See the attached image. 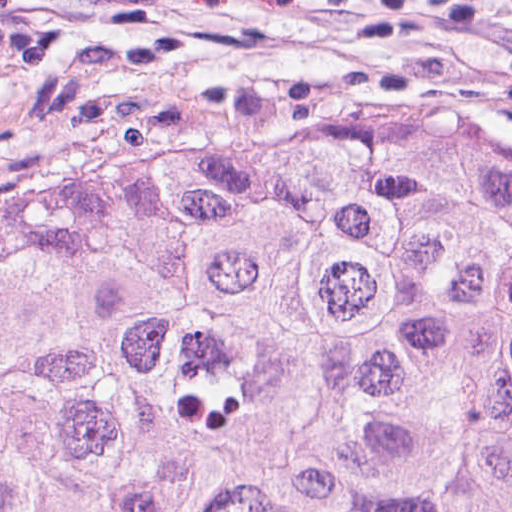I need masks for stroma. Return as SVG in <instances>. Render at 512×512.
Masks as SVG:
<instances>
[{
  "instance_id": "obj_1",
  "label": "stroma",
  "mask_w": 512,
  "mask_h": 512,
  "mask_svg": "<svg viewBox=\"0 0 512 512\" xmlns=\"http://www.w3.org/2000/svg\"><path fill=\"white\" fill-rule=\"evenodd\" d=\"M512 132V50L385 0H0V176L79 140Z\"/></svg>"
}]
</instances>
